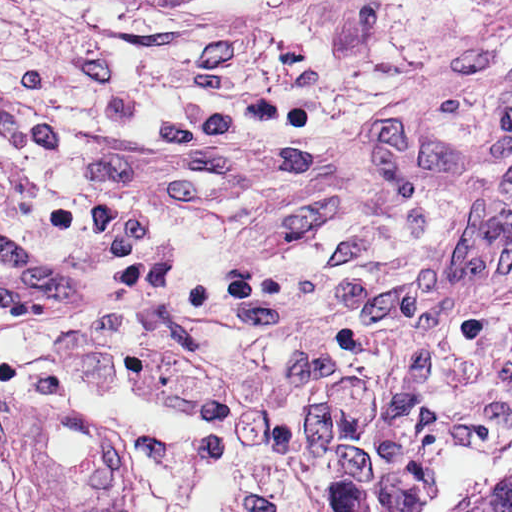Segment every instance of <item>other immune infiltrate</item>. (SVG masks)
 Instances as JSON below:
<instances>
[{"mask_svg": "<svg viewBox=\"0 0 512 512\" xmlns=\"http://www.w3.org/2000/svg\"><path fill=\"white\" fill-rule=\"evenodd\" d=\"M55 395L88 408L0 389V512H203L166 432Z\"/></svg>", "mask_w": 512, "mask_h": 512, "instance_id": "bc1004c8", "label": "other immune infiltrate"}]
</instances>
